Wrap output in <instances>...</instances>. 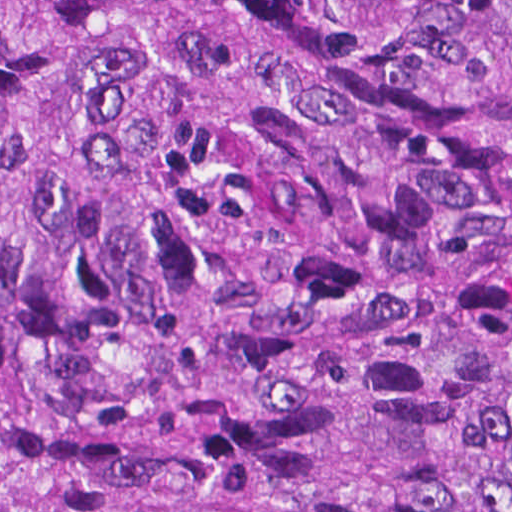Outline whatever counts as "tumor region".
I'll list each match as a JSON object with an SVG mask.
<instances>
[{
	"mask_svg": "<svg viewBox=\"0 0 512 512\" xmlns=\"http://www.w3.org/2000/svg\"><path fill=\"white\" fill-rule=\"evenodd\" d=\"M0 512H512V0H0Z\"/></svg>",
	"mask_w": 512,
	"mask_h": 512,
	"instance_id": "e687c5a6",
	"label": "tumor region"
}]
</instances>
